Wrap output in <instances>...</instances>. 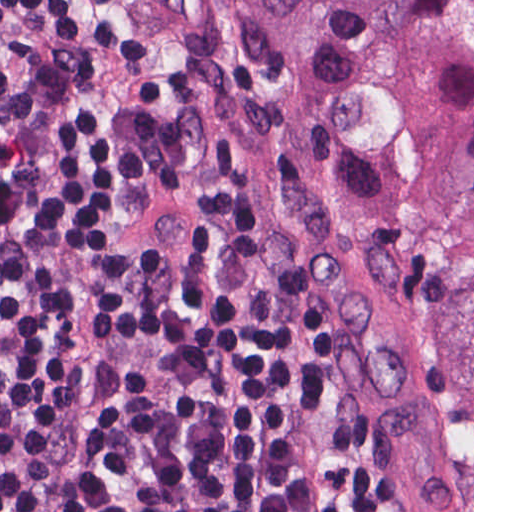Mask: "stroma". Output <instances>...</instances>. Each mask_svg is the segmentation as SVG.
Here are the masks:
<instances>
[{
	"label": "stroma",
	"mask_w": 512,
	"mask_h": 512,
	"mask_svg": "<svg viewBox=\"0 0 512 512\" xmlns=\"http://www.w3.org/2000/svg\"><path fill=\"white\" fill-rule=\"evenodd\" d=\"M99 2L208 144L249 185L296 290L401 441L430 512H453L437 448V328L416 301L362 166L289 40L253 0ZM10 310L11 267L0 242V320Z\"/></svg>",
	"instance_id": "35a3bbf8"
}]
</instances>
